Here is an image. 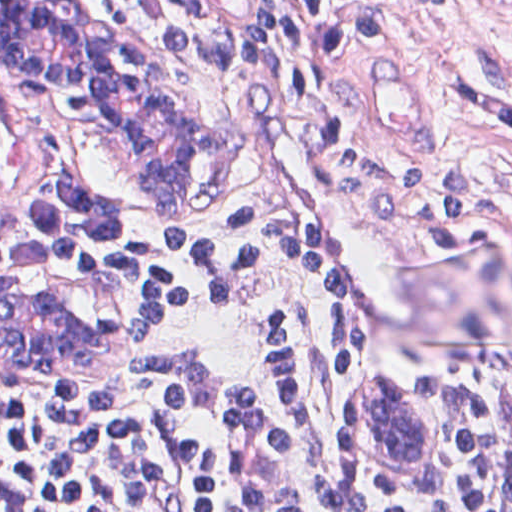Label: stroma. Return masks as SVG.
Wrapping results in <instances>:
<instances>
[{"instance_id": "35a3bbf8", "label": "stroma", "mask_w": 512, "mask_h": 512, "mask_svg": "<svg viewBox=\"0 0 512 512\" xmlns=\"http://www.w3.org/2000/svg\"><path fill=\"white\" fill-rule=\"evenodd\" d=\"M65 1L76 22L132 45L160 73L197 136L199 170L181 199L158 198L136 184L124 147H92L58 121L135 226L85 261L0 268V287L27 290L30 277L92 342L71 358L0 349V414L67 418L128 358L137 250L150 236L186 219L285 207L366 310L370 351L353 396L391 383L418 433L407 463L376 470L347 432L349 400L334 438L343 471L361 492L431 502L445 425L424 372L512 359V0L423 3L397 48L366 71L362 118L338 146L264 129L146 0ZM0 96L41 110L1 82Z\"/></svg>"}]
</instances>
